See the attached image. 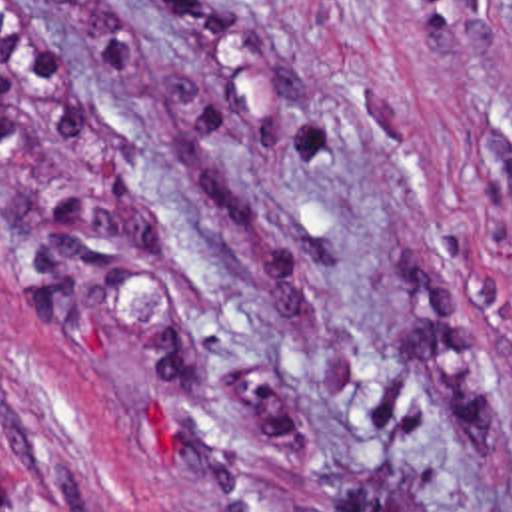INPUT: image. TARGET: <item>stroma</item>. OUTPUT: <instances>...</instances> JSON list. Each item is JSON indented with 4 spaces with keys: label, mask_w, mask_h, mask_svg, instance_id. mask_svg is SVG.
Segmentation results:
<instances>
[{
    "label": "stroma",
    "mask_w": 512,
    "mask_h": 512,
    "mask_svg": "<svg viewBox=\"0 0 512 512\" xmlns=\"http://www.w3.org/2000/svg\"><path fill=\"white\" fill-rule=\"evenodd\" d=\"M0 512H512V0H0Z\"/></svg>",
    "instance_id": "35a3bbf8"
}]
</instances>
